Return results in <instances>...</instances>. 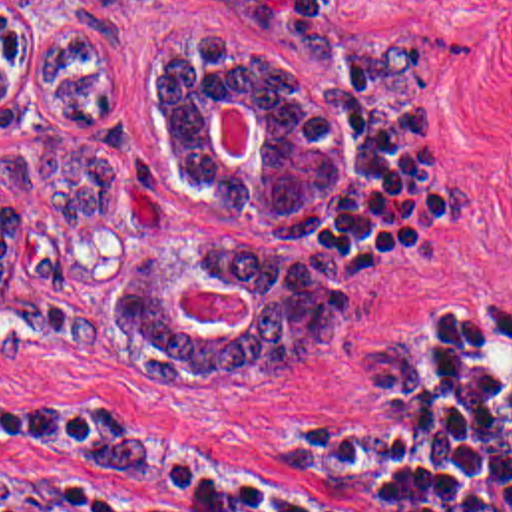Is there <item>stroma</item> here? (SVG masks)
Here are the masks:
<instances>
[{
	"label": "stroma",
	"instance_id": "stroma-1",
	"mask_svg": "<svg viewBox=\"0 0 512 512\" xmlns=\"http://www.w3.org/2000/svg\"><path fill=\"white\" fill-rule=\"evenodd\" d=\"M29 63L3 131H61L110 158L95 218L17 202L0 298V479H71L164 511L284 493L363 437L369 322L485 310L512 292V0H3ZM120 63V101L65 121L37 67L65 29ZM210 29L280 61L337 121V206L314 240H282L180 186L152 95L170 41ZM226 160L252 149V109L220 103ZM240 242L341 256V318L304 356L152 380L114 304L150 248ZM194 324H248L238 288L192 284Z\"/></svg>",
	"mask_w": 512,
	"mask_h": 512
}]
</instances>
